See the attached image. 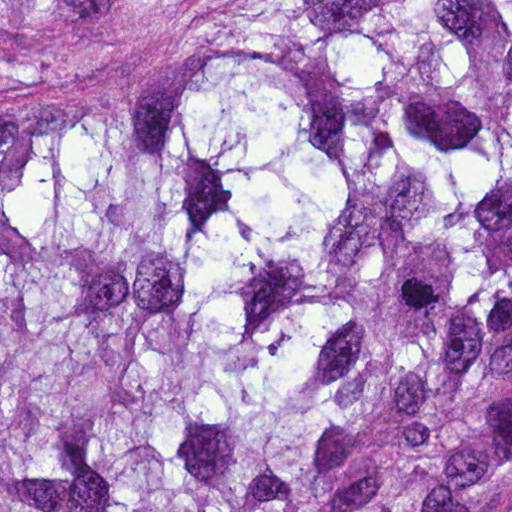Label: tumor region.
I'll use <instances>...</instances> for the list:
<instances>
[{
    "label": "tumor region",
    "instance_id": "tumor-region-1",
    "mask_svg": "<svg viewBox=\"0 0 512 512\" xmlns=\"http://www.w3.org/2000/svg\"><path fill=\"white\" fill-rule=\"evenodd\" d=\"M0 512H512V0H0Z\"/></svg>",
    "mask_w": 512,
    "mask_h": 512
}]
</instances>
